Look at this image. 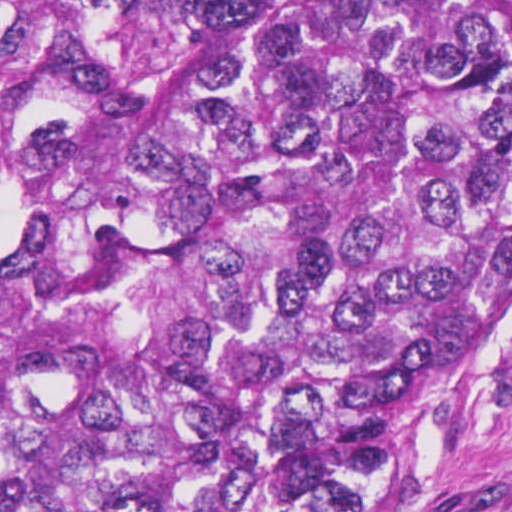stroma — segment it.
<instances>
[{
    "instance_id": "35a3bbf8",
    "label": "stroma",
    "mask_w": 512,
    "mask_h": 512,
    "mask_svg": "<svg viewBox=\"0 0 512 512\" xmlns=\"http://www.w3.org/2000/svg\"><path fill=\"white\" fill-rule=\"evenodd\" d=\"M354 512H512V307Z\"/></svg>"
}]
</instances>
